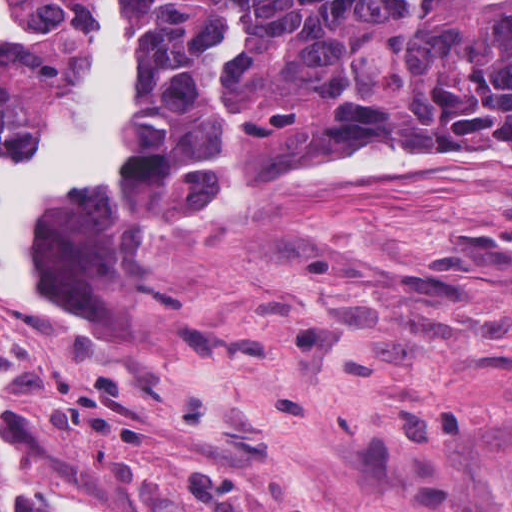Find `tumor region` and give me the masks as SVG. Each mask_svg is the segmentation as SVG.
<instances>
[{"label": "tumor region", "instance_id": "obj_1", "mask_svg": "<svg viewBox=\"0 0 512 512\" xmlns=\"http://www.w3.org/2000/svg\"><path fill=\"white\" fill-rule=\"evenodd\" d=\"M92 0H0V129L60 111ZM160 100L112 199L144 211L247 203L325 138L512 137V0H152ZM0 512H98L0 470Z\"/></svg>", "mask_w": 512, "mask_h": 512}]
</instances>
